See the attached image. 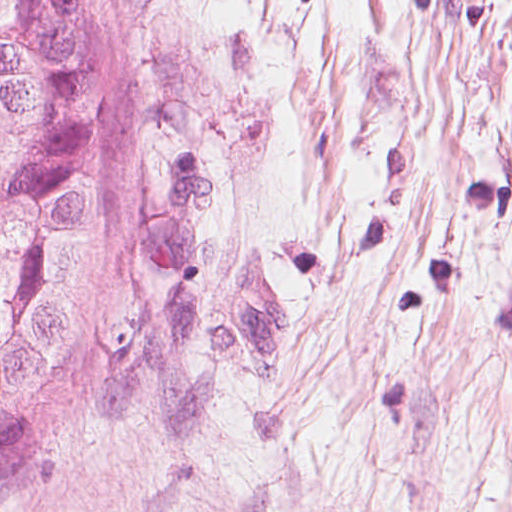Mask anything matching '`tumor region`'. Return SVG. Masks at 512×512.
<instances>
[{"instance_id":"1","label":"tumor region","mask_w":512,"mask_h":512,"mask_svg":"<svg viewBox=\"0 0 512 512\" xmlns=\"http://www.w3.org/2000/svg\"><path fill=\"white\" fill-rule=\"evenodd\" d=\"M139 0H0V482L94 377L143 168Z\"/></svg>"}]
</instances>
